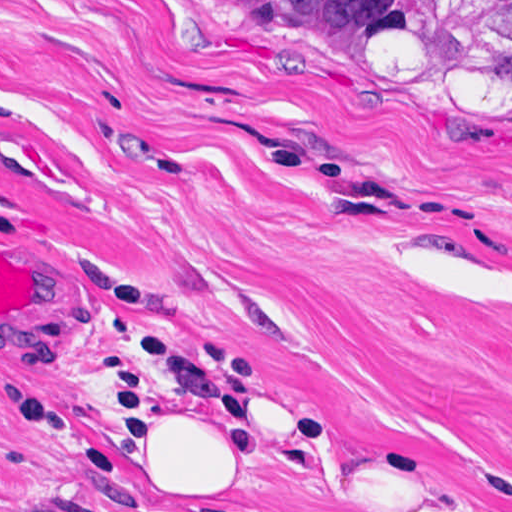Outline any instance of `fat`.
I'll use <instances>...</instances> for the list:
<instances>
[{"label":"fat","mask_w":512,"mask_h":512,"mask_svg":"<svg viewBox=\"0 0 512 512\" xmlns=\"http://www.w3.org/2000/svg\"><path fill=\"white\" fill-rule=\"evenodd\" d=\"M22 138L0 67V158ZM90 441L173 491L220 475L224 396L214 373L185 361L156 366L82 408Z\"/></svg>","instance_id":"53f6f03d"}]
</instances>
